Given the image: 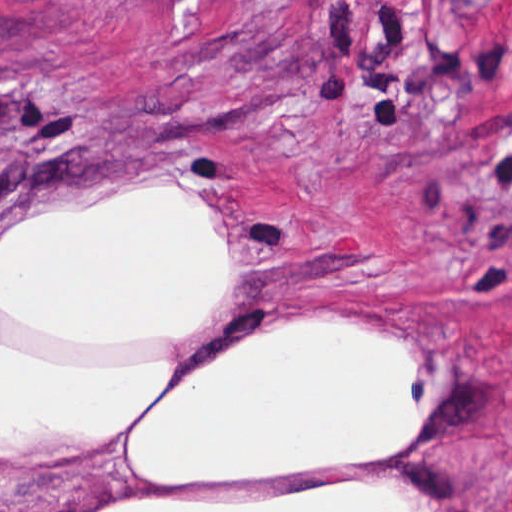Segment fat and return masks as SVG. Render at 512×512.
I'll return each instance as SVG.
<instances>
[{"mask_svg":"<svg viewBox=\"0 0 512 512\" xmlns=\"http://www.w3.org/2000/svg\"><path fill=\"white\" fill-rule=\"evenodd\" d=\"M236 231L183 181L31 215L0 244V460L122 439L159 486L286 483L392 461L434 420L415 338L276 325L173 378L226 294ZM86 512H430L403 483L122 495Z\"/></svg>","mask_w":512,"mask_h":512,"instance_id":"1","label":"fat"}]
</instances>
